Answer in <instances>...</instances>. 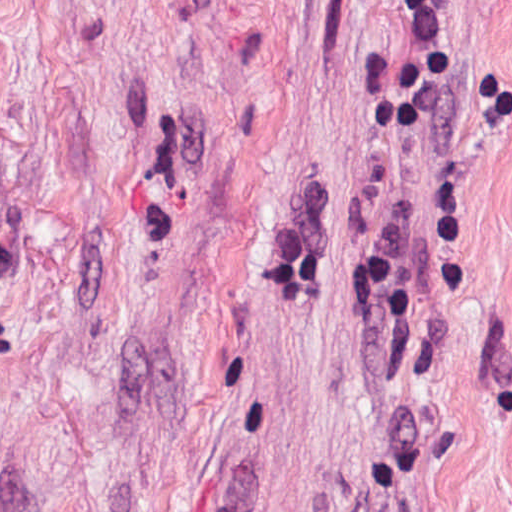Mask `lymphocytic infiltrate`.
<instances>
[{"label": "lymphocytic infiltrate", "instance_id": "1", "mask_svg": "<svg viewBox=\"0 0 512 512\" xmlns=\"http://www.w3.org/2000/svg\"><path fill=\"white\" fill-rule=\"evenodd\" d=\"M411 13L410 51L362 66L355 98L361 106L362 129L370 138H413L426 123L429 106L441 84L445 50V13L441 0H404ZM471 116L480 122H500L512 111L511 88L499 74L487 70L469 93ZM459 171L436 191L433 210V250L446 293L460 303Z\"/></svg>", "mask_w": 512, "mask_h": 512}]
</instances>
